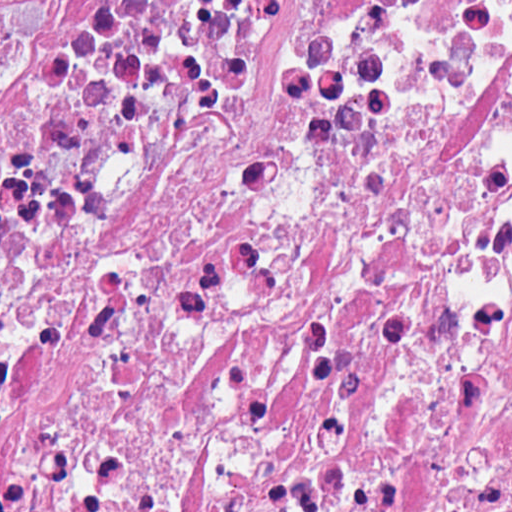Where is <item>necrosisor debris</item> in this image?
<instances>
[{
	"instance_id": "1",
	"label": "necrosis or debris",
	"mask_w": 512,
	"mask_h": 512,
	"mask_svg": "<svg viewBox=\"0 0 512 512\" xmlns=\"http://www.w3.org/2000/svg\"><path fill=\"white\" fill-rule=\"evenodd\" d=\"M0 512H512V0H0Z\"/></svg>"
}]
</instances>
